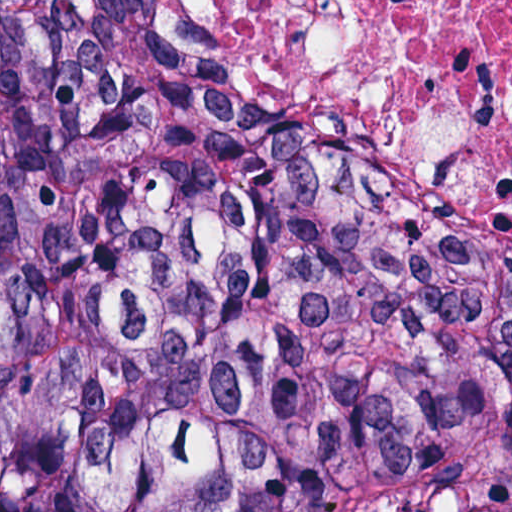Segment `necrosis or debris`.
<instances>
[{"instance_id": "necrosis-or-debris-1", "label": "necrosis or debris", "mask_w": 512, "mask_h": 512, "mask_svg": "<svg viewBox=\"0 0 512 512\" xmlns=\"http://www.w3.org/2000/svg\"><path fill=\"white\" fill-rule=\"evenodd\" d=\"M164 50L512 265V0H131Z\"/></svg>"}]
</instances>
